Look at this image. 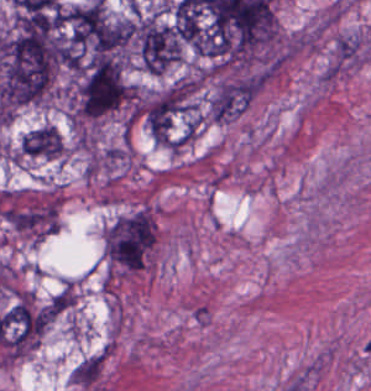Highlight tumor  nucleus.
Here are the masks:
<instances>
[{
	"label": "tumor nucleus",
	"mask_w": 371,
	"mask_h": 391,
	"mask_svg": "<svg viewBox=\"0 0 371 391\" xmlns=\"http://www.w3.org/2000/svg\"><path fill=\"white\" fill-rule=\"evenodd\" d=\"M132 41L139 62L148 72L160 74L180 60L177 29L154 15L133 22Z\"/></svg>",
	"instance_id": "1"
},
{
	"label": "tumor nucleus",
	"mask_w": 371,
	"mask_h": 391,
	"mask_svg": "<svg viewBox=\"0 0 371 391\" xmlns=\"http://www.w3.org/2000/svg\"><path fill=\"white\" fill-rule=\"evenodd\" d=\"M63 145L56 128L43 125L21 138V155L34 158L58 159Z\"/></svg>",
	"instance_id": "2"
}]
</instances>
